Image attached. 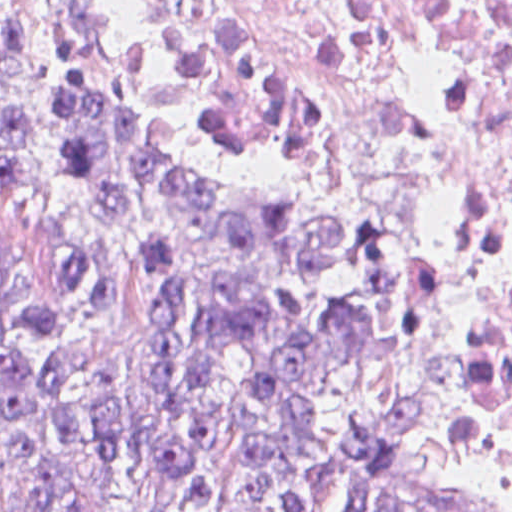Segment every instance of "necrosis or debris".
I'll return each instance as SVG.
<instances>
[{"instance_id":"obj_1","label":"necrosis or debris","mask_w":512,"mask_h":512,"mask_svg":"<svg viewBox=\"0 0 512 512\" xmlns=\"http://www.w3.org/2000/svg\"><path fill=\"white\" fill-rule=\"evenodd\" d=\"M162 124L288 165L438 296L512 503V0H86Z\"/></svg>"}]
</instances>
